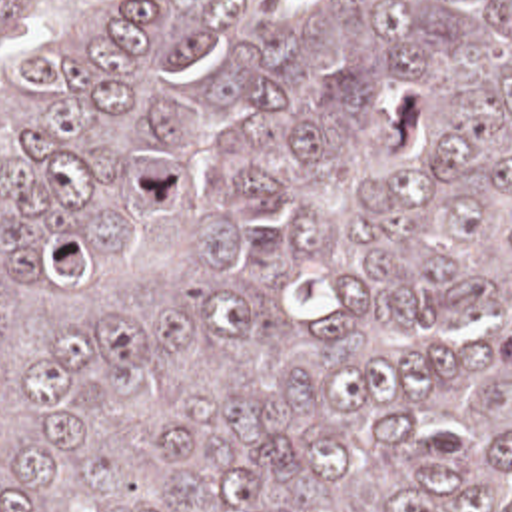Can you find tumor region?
Here are the masks:
<instances>
[{"label":"tumor region","mask_w":512,"mask_h":512,"mask_svg":"<svg viewBox=\"0 0 512 512\" xmlns=\"http://www.w3.org/2000/svg\"><path fill=\"white\" fill-rule=\"evenodd\" d=\"M0 512H512V0H0Z\"/></svg>","instance_id":"e687c5a6"}]
</instances>
